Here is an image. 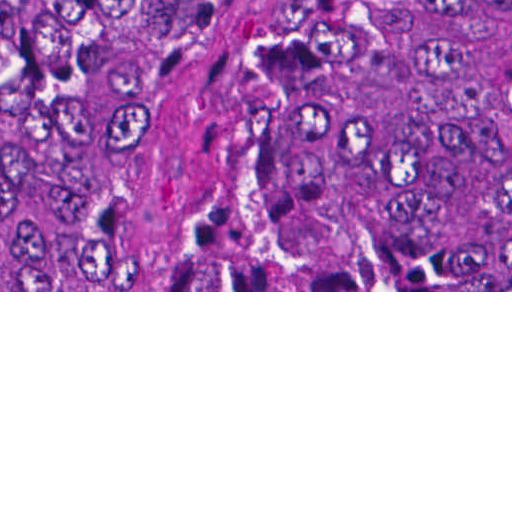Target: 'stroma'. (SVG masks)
I'll return each mask as SVG.
<instances>
[{"label": "stroma", "mask_w": 512, "mask_h": 512, "mask_svg": "<svg viewBox=\"0 0 512 512\" xmlns=\"http://www.w3.org/2000/svg\"><path fill=\"white\" fill-rule=\"evenodd\" d=\"M367 275L306 266L268 235L222 121L221 82L118 290H1L0 0V292H512L362 290Z\"/></svg>", "instance_id": "1"}]
</instances>
